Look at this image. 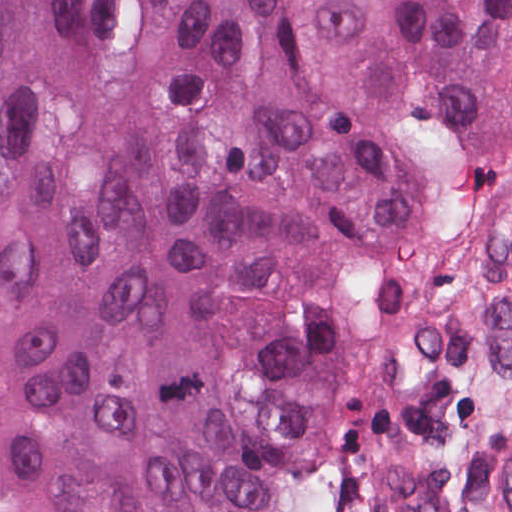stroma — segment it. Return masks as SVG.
I'll return each instance as SVG.
<instances>
[{"label":"stroma","instance_id":"1","mask_svg":"<svg viewBox=\"0 0 512 512\" xmlns=\"http://www.w3.org/2000/svg\"><path fill=\"white\" fill-rule=\"evenodd\" d=\"M512 154L457 183L312 392L311 493L367 512L357 476L391 466L454 512H509Z\"/></svg>","mask_w":512,"mask_h":512}]
</instances>
